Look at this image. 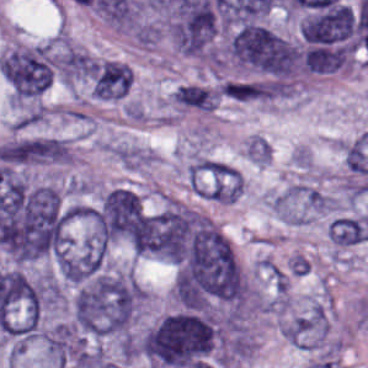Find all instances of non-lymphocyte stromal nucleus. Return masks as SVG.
<instances>
[{
  "instance_id": "non-lymphocyte-stromal-nucleus-1",
  "label": "non-lymphocyte stromal nucleus",
  "mask_w": 368,
  "mask_h": 368,
  "mask_svg": "<svg viewBox=\"0 0 368 368\" xmlns=\"http://www.w3.org/2000/svg\"><path fill=\"white\" fill-rule=\"evenodd\" d=\"M72 46L62 32L7 48L0 68L11 99L27 106L43 96Z\"/></svg>"
},
{
  "instance_id": "non-lymphocyte-stromal-nucleus-2",
  "label": "non-lymphocyte stromal nucleus",
  "mask_w": 368,
  "mask_h": 368,
  "mask_svg": "<svg viewBox=\"0 0 368 368\" xmlns=\"http://www.w3.org/2000/svg\"><path fill=\"white\" fill-rule=\"evenodd\" d=\"M196 195L222 202L236 201L242 179L237 169L218 160L195 156L186 168Z\"/></svg>"
},
{
  "instance_id": "non-lymphocyte-stromal-nucleus-3",
  "label": "non-lymphocyte stromal nucleus",
  "mask_w": 368,
  "mask_h": 368,
  "mask_svg": "<svg viewBox=\"0 0 368 368\" xmlns=\"http://www.w3.org/2000/svg\"><path fill=\"white\" fill-rule=\"evenodd\" d=\"M327 205L323 195L306 184H293L272 201V210L285 223H306Z\"/></svg>"
},
{
  "instance_id": "non-lymphocyte-stromal-nucleus-4",
  "label": "non-lymphocyte stromal nucleus",
  "mask_w": 368,
  "mask_h": 368,
  "mask_svg": "<svg viewBox=\"0 0 368 368\" xmlns=\"http://www.w3.org/2000/svg\"><path fill=\"white\" fill-rule=\"evenodd\" d=\"M133 82L130 66L121 61L98 59L91 71V90L98 100L115 101L127 96Z\"/></svg>"
},
{
  "instance_id": "non-lymphocyte-stromal-nucleus-5",
  "label": "non-lymphocyte stromal nucleus",
  "mask_w": 368,
  "mask_h": 368,
  "mask_svg": "<svg viewBox=\"0 0 368 368\" xmlns=\"http://www.w3.org/2000/svg\"><path fill=\"white\" fill-rule=\"evenodd\" d=\"M330 241L339 247H350L368 240V216H337L328 227Z\"/></svg>"
},
{
  "instance_id": "non-lymphocyte-stromal-nucleus-6",
  "label": "non-lymphocyte stromal nucleus",
  "mask_w": 368,
  "mask_h": 368,
  "mask_svg": "<svg viewBox=\"0 0 368 368\" xmlns=\"http://www.w3.org/2000/svg\"><path fill=\"white\" fill-rule=\"evenodd\" d=\"M172 98L179 110L211 112L219 103L220 94L210 86L190 83L178 87Z\"/></svg>"
},
{
  "instance_id": "non-lymphocyte-stromal-nucleus-7",
  "label": "non-lymphocyte stromal nucleus",
  "mask_w": 368,
  "mask_h": 368,
  "mask_svg": "<svg viewBox=\"0 0 368 368\" xmlns=\"http://www.w3.org/2000/svg\"><path fill=\"white\" fill-rule=\"evenodd\" d=\"M220 96L233 101H258L261 83L254 79H228L222 82Z\"/></svg>"
}]
</instances>
